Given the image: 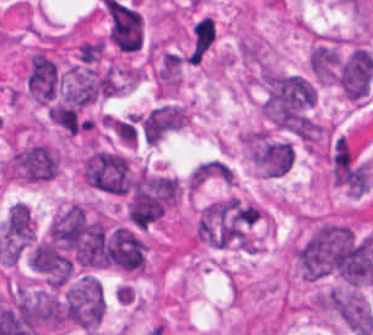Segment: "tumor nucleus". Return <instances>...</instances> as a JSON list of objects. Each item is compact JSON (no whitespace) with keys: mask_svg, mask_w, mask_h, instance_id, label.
I'll return each mask as SVG.
<instances>
[{"mask_svg":"<svg viewBox=\"0 0 373 335\" xmlns=\"http://www.w3.org/2000/svg\"><path fill=\"white\" fill-rule=\"evenodd\" d=\"M177 199V185L171 177L141 172L133 182L127 207L134 226L147 228L159 220Z\"/></svg>","mask_w":373,"mask_h":335,"instance_id":"obj_5","label":"tumor nucleus"},{"mask_svg":"<svg viewBox=\"0 0 373 335\" xmlns=\"http://www.w3.org/2000/svg\"><path fill=\"white\" fill-rule=\"evenodd\" d=\"M1 232L9 240H35V224L30 209L21 202H14L1 223Z\"/></svg>","mask_w":373,"mask_h":335,"instance_id":"obj_14","label":"tumor nucleus"},{"mask_svg":"<svg viewBox=\"0 0 373 335\" xmlns=\"http://www.w3.org/2000/svg\"><path fill=\"white\" fill-rule=\"evenodd\" d=\"M105 315L103 288L95 274L82 273L63 290V322L95 333Z\"/></svg>","mask_w":373,"mask_h":335,"instance_id":"obj_7","label":"tumor nucleus"},{"mask_svg":"<svg viewBox=\"0 0 373 335\" xmlns=\"http://www.w3.org/2000/svg\"><path fill=\"white\" fill-rule=\"evenodd\" d=\"M311 306L348 331L370 335L373 330V312L360 289L327 287L313 296Z\"/></svg>","mask_w":373,"mask_h":335,"instance_id":"obj_6","label":"tumor nucleus"},{"mask_svg":"<svg viewBox=\"0 0 373 335\" xmlns=\"http://www.w3.org/2000/svg\"><path fill=\"white\" fill-rule=\"evenodd\" d=\"M262 218L258 204L226 197L203 208L195 236L213 247L255 251Z\"/></svg>","mask_w":373,"mask_h":335,"instance_id":"obj_3","label":"tumor nucleus"},{"mask_svg":"<svg viewBox=\"0 0 373 335\" xmlns=\"http://www.w3.org/2000/svg\"><path fill=\"white\" fill-rule=\"evenodd\" d=\"M61 167L56 148L45 142H31L11 153L4 163V177L19 182H45L59 175Z\"/></svg>","mask_w":373,"mask_h":335,"instance_id":"obj_8","label":"tumor nucleus"},{"mask_svg":"<svg viewBox=\"0 0 373 335\" xmlns=\"http://www.w3.org/2000/svg\"><path fill=\"white\" fill-rule=\"evenodd\" d=\"M232 181V172L221 159H208L196 166L190 175L189 186L198 187Z\"/></svg>","mask_w":373,"mask_h":335,"instance_id":"obj_15","label":"tumor nucleus"},{"mask_svg":"<svg viewBox=\"0 0 373 335\" xmlns=\"http://www.w3.org/2000/svg\"><path fill=\"white\" fill-rule=\"evenodd\" d=\"M145 241L127 226L115 225L104 237L98 264L128 272H143Z\"/></svg>","mask_w":373,"mask_h":335,"instance_id":"obj_9","label":"tumor nucleus"},{"mask_svg":"<svg viewBox=\"0 0 373 335\" xmlns=\"http://www.w3.org/2000/svg\"><path fill=\"white\" fill-rule=\"evenodd\" d=\"M187 113L182 105L165 104L153 109L139 120L144 139L157 144L186 126Z\"/></svg>","mask_w":373,"mask_h":335,"instance_id":"obj_12","label":"tumor nucleus"},{"mask_svg":"<svg viewBox=\"0 0 373 335\" xmlns=\"http://www.w3.org/2000/svg\"><path fill=\"white\" fill-rule=\"evenodd\" d=\"M260 109L271 126H315L316 89L306 75L266 68L262 72Z\"/></svg>","mask_w":373,"mask_h":335,"instance_id":"obj_2","label":"tumor nucleus"},{"mask_svg":"<svg viewBox=\"0 0 373 335\" xmlns=\"http://www.w3.org/2000/svg\"><path fill=\"white\" fill-rule=\"evenodd\" d=\"M80 181L98 192L128 194L132 173L126 155L118 150L91 147L79 160Z\"/></svg>","mask_w":373,"mask_h":335,"instance_id":"obj_4","label":"tumor nucleus"},{"mask_svg":"<svg viewBox=\"0 0 373 335\" xmlns=\"http://www.w3.org/2000/svg\"><path fill=\"white\" fill-rule=\"evenodd\" d=\"M340 56L338 46L316 42L309 52V68L316 84H336Z\"/></svg>","mask_w":373,"mask_h":335,"instance_id":"obj_13","label":"tumor nucleus"},{"mask_svg":"<svg viewBox=\"0 0 373 335\" xmlns=\"http://www.w3.org/2000/svg\"><path fill=\"white\" fill-rule=\"evenodd\" d=\"M109 38L118 51H138L142 35L139 13L119 3L106 2Z\"/></svg>","mask_w":373,"mask_h":335,"instance_id":"obj_11","label":"tumor nucleus"},{"mask_svg":"<svg viewBox=\"0 0 373 335\" xmlns=\"http://www.w3.org/2000/svg\"><path fill=\"white\" fill-rule=\"evenodd\" d=\"M247 133L256 166L285 173L293 167V144L266 128H252Z\"/></svg>","mask_w":373,"mask_h":335,"instance_id":"obj_10","label":"tumor nucleus"},{"mask_svg":"<svg viewBox=\"0 0 373 335\" xmlns=\"http://www.w3.org/2000/svg\"><path fill=\"white\" fill-rule=\"evenodd\" d=\"M294 260L303 278L358 285L369 279V239L349 222L326 219L295 245Z\"/></svg>","mask_w":373,"mask_h":335,"instance_id":"obj_1","label":"tumor nucleus"}]
</instances>
